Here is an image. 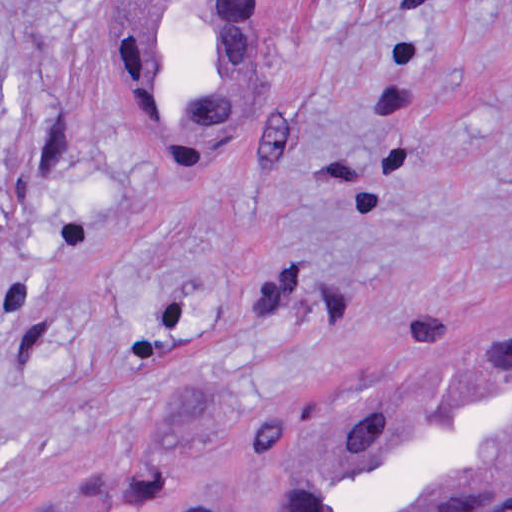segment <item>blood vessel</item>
Segmentation results:
<instances>
[{"label": "blood vessel", "mask_w": 512, "mask_h": 512, "mask_svg": "<svg viewBox=\"0 0 512 512\" xmlns=\"http://www.w3.org/2000/svg\"><path fill=\"white\" fill-rule=\"evenodd\" d=\"M278 1H142L121 80L160 170L210 177L254 119ZM512 500V339L325 440L283 455L266 512H493Z\"/></svg>", "instance_id": "obj_1"}]
</instances>
